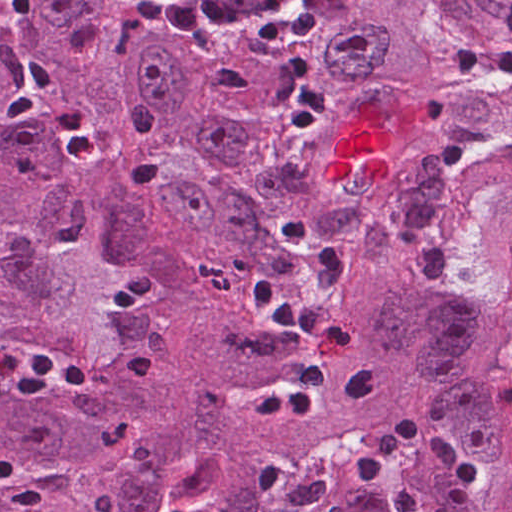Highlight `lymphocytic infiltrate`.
Here are the masks:
<instances>
[{"mask_svg":"<svg viewBox=\"0 0 512 512\" xmlns=\"http://www.w3.org/2000/svg\"><path fill=\"white\" fill-rule=\"evenodd\" d=\"M0 15L12 25H24L34 16V0H0ZM256 307L281 326L302 334L311 345L307 363L294 388L269 396L255 407V418L307 416L319 392L335 374L349 351V336L320 319L310 308L278 294L261 276L249 286ZM0 368L9 387L29 398H47L60 388L93 385L91 375L61 364L41 350L20 355L1 354ZM427 460L449 469L461 482L458 505L467 509L483 487V471L442 433L406 416H388L373 438L345 467L342 475L370 483L404 444Z\"/></svg>","mask_w":512,"mask_h":512,"instance_id":"obj_1","label":"lymphocytic infiltrate"}]
</instances>
